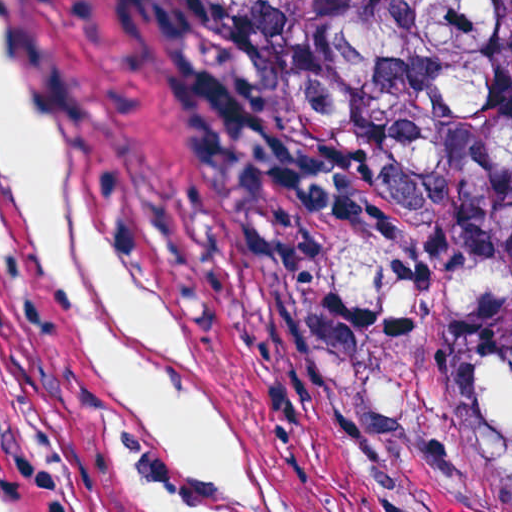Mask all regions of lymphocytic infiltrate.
Instances as JSON below:
<instances>
[{
    "label": "lymphocytic infiltrate",
    "instance_id": "f902f5d3",
    "mask_svg": "<svg viewBox=\"0 0 512 512\" xmlns=\"http://www.w3.org/2000/svg\"><path fill=\"white\" fill-rule=\"evenodd\" d=\"M1 512H47L7 434L0 426Z\"/></svg>",
    "mask_w": 512,
    "mask_h": 512
}]
</instances>
